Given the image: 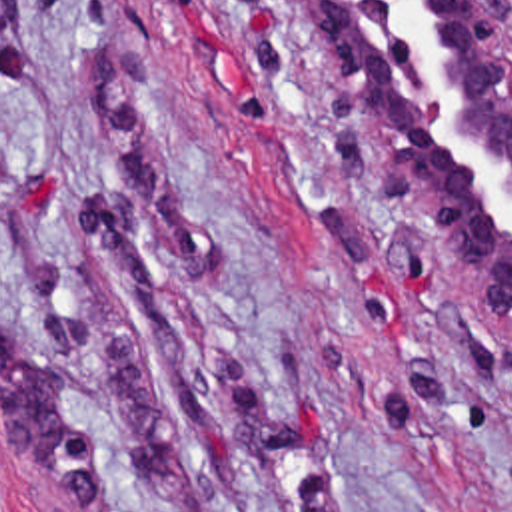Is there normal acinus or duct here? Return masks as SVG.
<instances>
[{
    "label": "normal acinus or duct",
    "instance_id": "obj_1",
    "mask_svg": "<svg viewBox=\"0 0 512 512\" xmlns=\"http://www.w3.org/2000/svg\"><path fill=\"white\" fill-rule=\"evenodd\" d=\"M342 116L404 180L446 300L512 320V54L479 0H284Z\"/></svg>",
    "mask_w": 512,
    "mask_h": 512
}]
</instances>
